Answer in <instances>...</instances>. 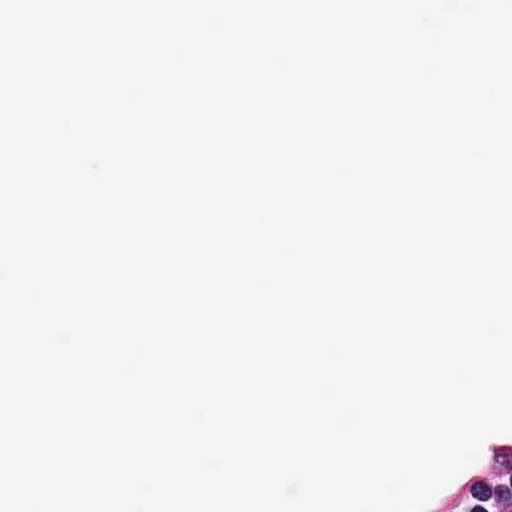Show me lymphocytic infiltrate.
<instances>
[{
  "instance_id": "lymphocytic-infiltrate-1",
  "label": "lymphocytic infiltrate",
  "mask_w": 512,
  "mask_h": 512,
  "mask_svg": "<svg viewBox=\"0 0 512 512\" xmlns=\"http://www.w3.org/2000/svg\"><path fill=\"white\" fill-rule=\"evenodd\" d=\"M406 512H512V448L486 457L458 483L437 486Z\"/></svg>"
}]
</instances>
